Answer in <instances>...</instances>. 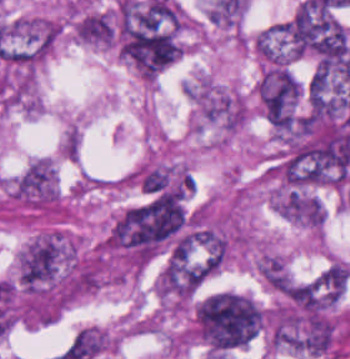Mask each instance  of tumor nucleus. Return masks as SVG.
<instances>
[{
    "label": "tumor nucleus",
    "mask_w": 350,
    "mask_h": 359,
    "mask_svg": "<svg viewBox=\"0 0 350 359\" xmlns=\"http://www.w3.org/2000/svg\"><path fill=\"white\" fill-rule=\"evenodd\" d=\"M264 313L251 295L222 290L195 307L192 330L208 351L224 355L261 335Z\"/></svg>",
    "instance_id": "tumor-nucleus-1"
},
{
    "label": "tumor nucleus",
    "mask_w": 350,
    "mask_h": 359,
    "mask_svg": "<svg viewBox=\"0 0 350 359\" xmlns=\"http://www.w3.org/2000/svg\"><path fill=\"white\" fill-rule=\"evenodd\" d=\"M61 24L50 17L28 14L12 21L0 59L7 64L33 70L51 53Z\"/></svg>",
    "instance_id": "tumor-nucleus-2"
},
{
    "label": "tumor nucleus",
    "mask_w": 350,
    "mask_h": 359,
    "mask_svg": "<svg viewBox=\"0 0 350 359\" xmlns=\"http://www.w3.org/2000/svg\"><path fill=\"white\" fill-rule=\"evenodd\" d=\"M270 207L288 222L305 230L319 232L326 221L321 200L309 192L276 187L271 192Z\"/></svg>",
    "instance_id": "tumor-nucleus-3"
},
{
    "label": "tumor nucleus",
    "mask_w": 350,
    "mask_h": 359,
    "mask_svg": "<svg viewBox=\"0 0 350 359\" xmlns=\"http://www.w3.org/2000/svg\"><path fill=\"white\" fill-rule=\"evenodd\" d=\"M256 270L272 288L292 278L284 259L271 250L262 251L256 261Z\"/></svg>",
    "instance_id": "tumor-nucleus-4"
}]
</instances>
